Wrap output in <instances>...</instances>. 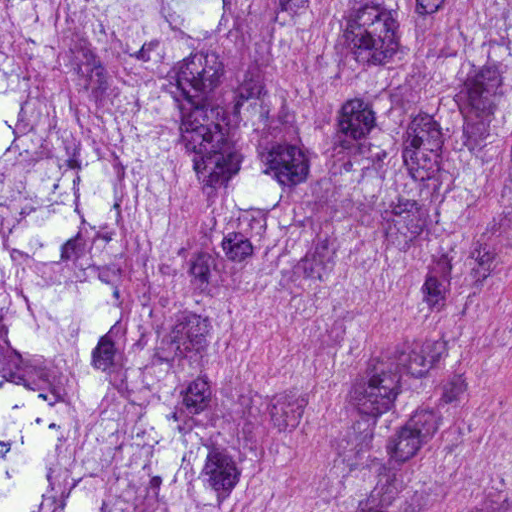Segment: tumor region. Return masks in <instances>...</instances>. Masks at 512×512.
<instances>
[{
  "label": "tumor region",
  "instance_id": "1",
  "mask_svg": "<svg viewBox=\"0 0 512 512\" xmlns=\"http://www.w3.org/2000/svg\"><path fill=\"white\" fill-rule=\"evenodd\" d=\"M314 1H0V512H236L266 428L223 324L311 221L261 128ZM337 170L422 257L512 204V1H351ZM351 512H509L362 463Z\"/></svg>",
  "mask_w": 512,
  "mask_h": 512
}]
</instances>
